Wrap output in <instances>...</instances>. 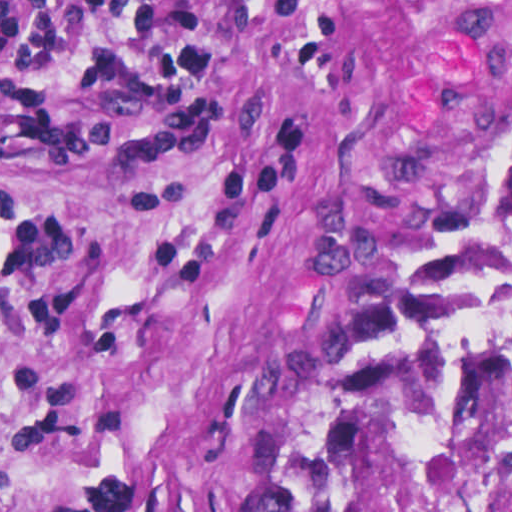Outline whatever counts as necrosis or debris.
I'll return each instance as SVG.
<instances>
[{
    "label": "necrosis or debris",
    "mask_w": 512,
    "mask_h": 512,
    "mask_svg": "<svg viewBox=\"0 0 512 512\" xmlns=\"http://www.w3.org/2000/svg\"><path fill=\"white\" fill-rule=\"evenodd\" d=\"M340 512H512V166L428 298Z\"/></svg>",
    "instance_id": "obj_1"
}]
</instances>
